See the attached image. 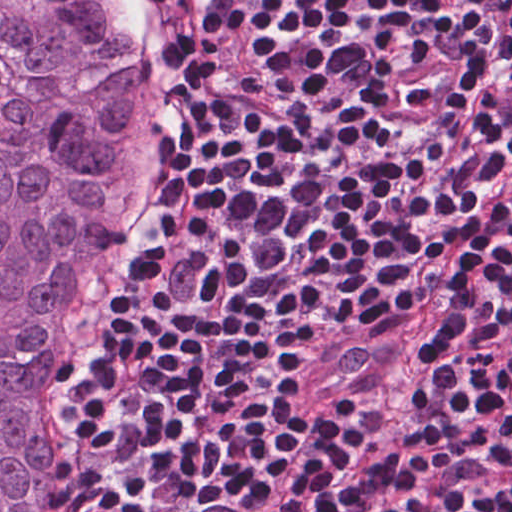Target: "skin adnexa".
Returning a JSON list of instances; mask_svg holds the SVG:
<instances>
[{"label": "skin adnexa", "instance_id": "skin-adnexa-1", "mask_svg": "<svg viewBox=\"0 0 512 512\" xmlns=\"http://www.w3.org/2000/svg\"><path fill=\"white\" fill-rule=\"evenodd\" d=\"M170 118V62L139 0H0V512H66L72 312Z\"/></svg>", "mask_w": 512, "mask_h": 512}]
</instances>
